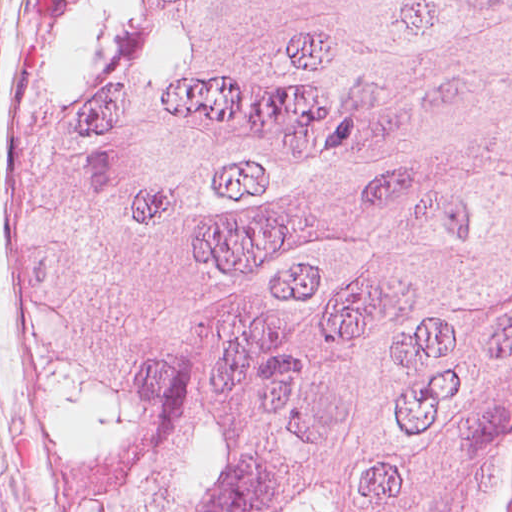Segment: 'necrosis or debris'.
<instances>
[{
    "instance_id": "1",
    "label": "necrosis or debris",
    "mask_w": 512,
    "mask_h": 512,
    "mask_svg": "<svg viewBox=\"0 0 512 512\" xmlns=\"http://www.w3.org/2000/svg\"><path fill=\"white\" fill-rule=\"evenodd\" d=\"M502 512H512V464L508 475V485Z\"/></svg>"
}]
</instances>
